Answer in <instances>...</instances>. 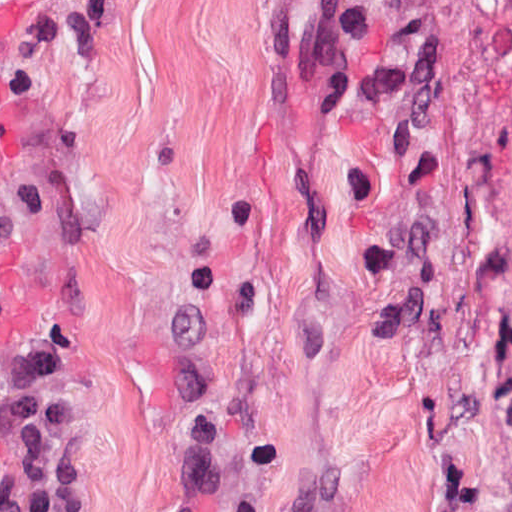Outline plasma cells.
Wrapping results in <instances>:
<instances>
[{
  "label": "plasma cells",
  "instance_id": "1",
  "mask_svg": "<svg viewBox=\"0 0 512 512\" xmlns=\"http://www.w3.org/2000/svg\"><path fill=\"white\" fill-rule=\"evenodd\" d=\"M46 81L31 68L0 75V112ZM3 332L0 311V343ZM68 366L67 351L53 342L12 360L0 356V432L10 456L0 512H90L89 432L63 385Z\"/></svg>",
  "mask_w": 512,
  "mask_h": 512
}]
</instances>
